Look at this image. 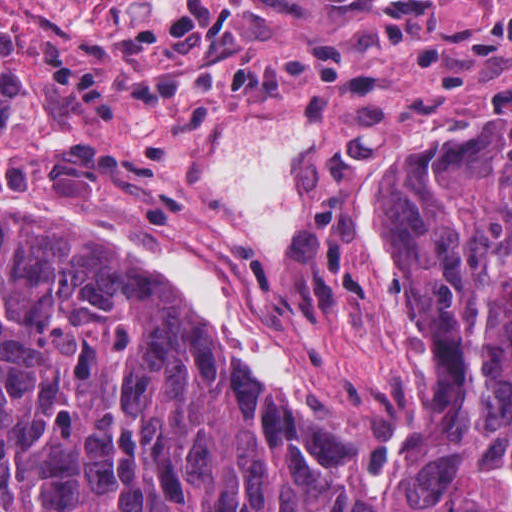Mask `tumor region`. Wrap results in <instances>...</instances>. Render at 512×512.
<instances>
[{
  "label": "tumor region",
  "instance_id": "1",
  "mask_svg": "<svg viewBox=\"0 0 512 512\" xmlns=\"http://www.w3.org/2000/svg\"><path fill=\"white\" fill-rule=\"evenodd\" d=\"M191 0L108 88L338 87V52L246 63ZM24 87L0 3V111ZM268 250L211 163L0 209V512H512V97L313 143Z\"/></svg>",
  "mask_w": 512,
  "mask_h": 512
}]
</instances>
